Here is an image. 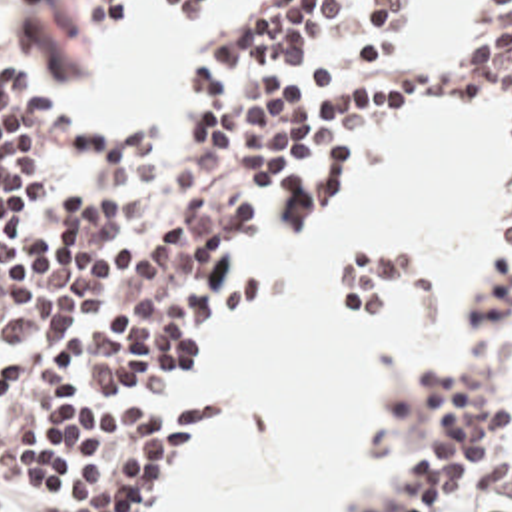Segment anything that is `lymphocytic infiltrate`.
I'll return each instance as SVG.
<instances>
[{"label": "lymphocytic infiltrate", "instance_id": "lymphocytic-infiltrate-1", "mask_svg": "<svg viewBox=\"0 0 512 512\" xmlns=\"http://www.w3.org/2000/svg\"><path fill=\"white\" fill-rule=\"evenodd\" d=\"M216 0H164L170 27ZM406 0H272L242 41L190 63L202 119L176 179L128 217L114 193L54 191L76 153L98 183L162 159L150 107L80 123L52 111L0 61V512H148L212 444L232 399L160 401L228 323L294 289L280 267L242 269L268 211L292 231L320 223L360 171L346 149L404 113L500 109L512 125V0H484L472 23H500L432 59L386 61ZM72 5L98 33L124 0ZM388 512H434L460 498L502 448V405L470 385L426 395ZM500 512V510H480Z\"/></svg>", "mask_w": 512, "mask_h": 512}]
</instances>
